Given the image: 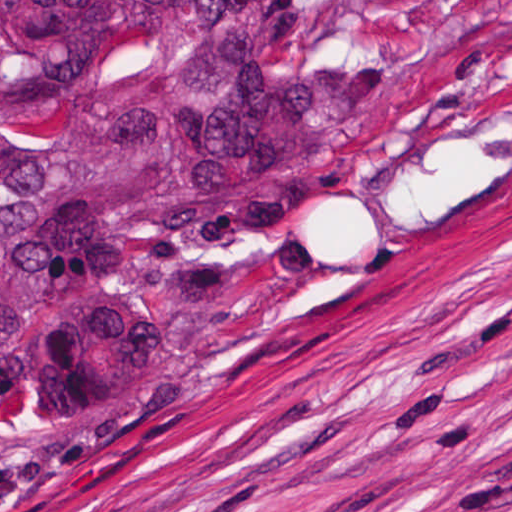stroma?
Masks as SVG:
<instances>
[{"label": "stroma", "instance_id": "obj_1", "mask_svg": "<svg viewBox=\"0 0 512 512\" xmlns=\"http://www.w3.org/2000/svg\"><path fill=\"white\" fill-rule=\"evenodd\" d=\"M0 426V512H512V164L226 370Z\"/></svg>", "mask_w": 512, "mask_h": 512}]
</instances>
